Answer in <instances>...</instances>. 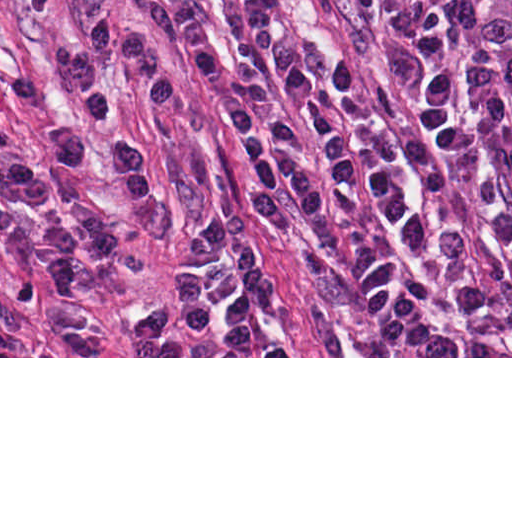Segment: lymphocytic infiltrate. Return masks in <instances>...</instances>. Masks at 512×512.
Segmentation results:
<instances>
[{
  "mask_svg": "<svg viewBox=\"0 0 512 512\" xmlns=\"http://www.w3.org/2000/svg\"><path fill=\"white\" fill-rule=\"evenodd\" d=\"M253 51H267L291 0H235ZM192 59L225 90L224 115L251 167L255 209L273 232L304 224L316 234L337 225L347 195L394 196L403 164V137L373 91L345 58L310 72L286 58L270 67L247 56L233 65L199 36L185 37ZM111 65L126 70L147 103H172V73L149 39L106 16L88 19L70 43L66 74L88 117L105 131L102 141L74 123L50 131L55 151L73 166L113 158L134 205L151 199L149 169L108 83ZM0 86L14 100L36 104L32 76L0 58ZM48 187L16 133L0 124V245L20 269L60 293H76L86 268L114 249V221L97 213L67 218L28 217L4 204L42 203ZM14 348V327L0 313V351Z\"/></svg>",
  "mask_w": 512,
  "mask_h": 512,
  "instance_id": "1",
  "label": "lymphocytic infiltrate"
}]
</instances>
